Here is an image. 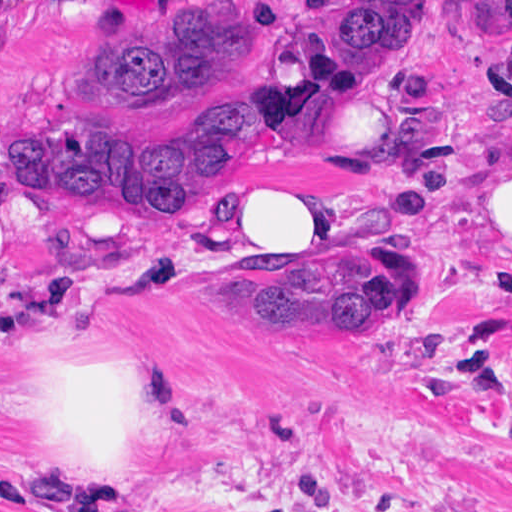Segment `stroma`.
<instances>
[{
  "label": "stroma",
  "mask_w": 512,
  "mask_h": 512,
  "mask_svg": "<svg viewBox=\"0 0 512 512\" xmlns=\"http://www.w3.org/2000/svg\"><path fill=\"white\" fill-rule=\"evenodd\" d=\"M201 1L0 0V152L82 112L70 88L118 21ZM262 1L272 30L313 0ZM238 77L265 96V52ZM231 86L102 121L204 148ZM504 149L512 0H428L397 74L325 113L302 157L266 149L196 212H103L0 175V492L37 512L113 496L75 455L50 385L84 368L127 389L147 503L119 512H512V225L481 210V172ZM255 172L317 193L337 257L338 241L424 251L438 292L363 333L267 335L228 319L174 273L234 249L212 215Z\"/></svg>",
  "instance_id": "stroma-1"
}]
</instances>
